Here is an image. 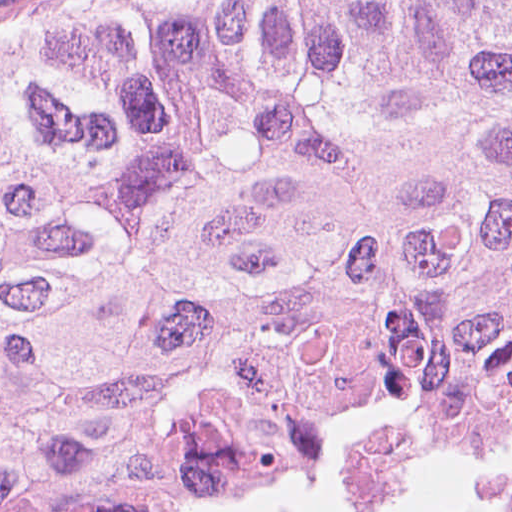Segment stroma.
<instances>
[{"label":"stroma","instance_id":"35a3bbf8","mask_svg":"<svg viewBox=\"0 0 512 512\" xmlns=\"http://www.w3.org/2000/svg\"><path fill=\"white\" fill-rule=\"evenodd\" d=\"M160 1L166 0H0V50L51 23ZM463 467H512V441H484L305 470L201 512H329L401 483Z\"/></svg>","mask_w":512,"mask_h":512}]
</instances>
